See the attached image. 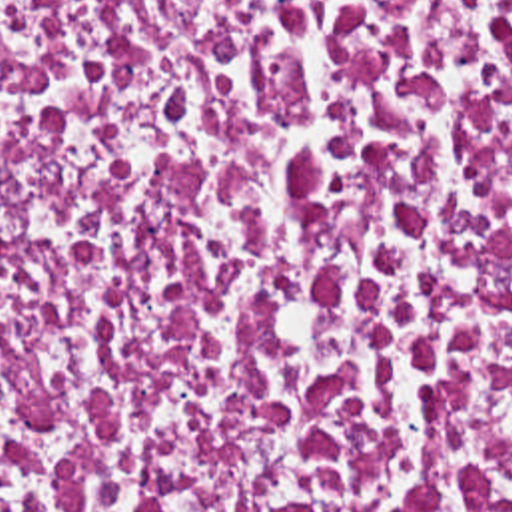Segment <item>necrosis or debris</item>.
Returning a JSON list of instances; mask_svg holds the SVG:
<instances>
[{
    "mask_svg": "<svg viewBox=\"0 0 512 512\" xmlns=\"http://www.w3.org/2000/svg\"><path fill=\"white\" fill-rule=\"evenodd\" d=\"M0 512H512V0H0Z\"/></svg>",
    "mask_w": 512,
    "mask_h": 512,
    "instance_id": "1",
    "label": "necrosis or debris"
}]
</instances>
